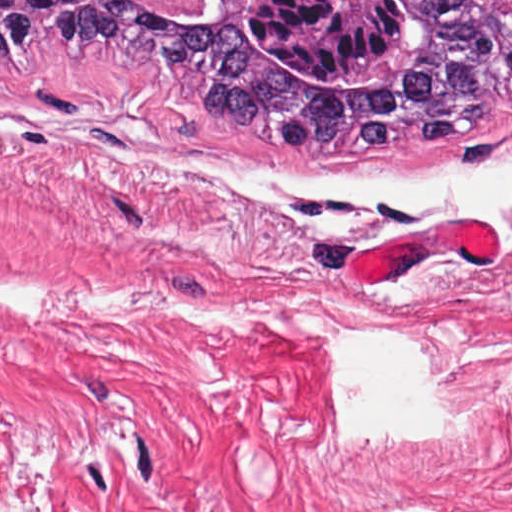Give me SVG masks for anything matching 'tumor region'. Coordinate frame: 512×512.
Wrapping results in <instances>:
<instances>
[{"instance_id":"e687c5a6","label":"tumor region","mask_w":512,"mask_h":512,"mask_svg":"<svg viewBox=\"0 0 512 512\" xmlns=\"http://www.w3.org/2000/svg\"><path fill=\"white\" fill-rule=\"evenodd\" d=\"M71 46L298 155H403L512 102V0H0L1 60Z\"/></svg>"}]
</instances>
